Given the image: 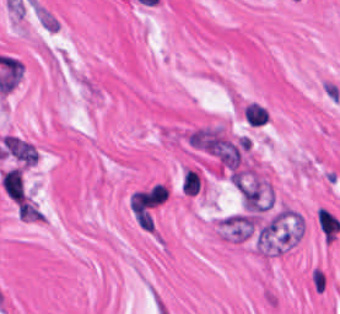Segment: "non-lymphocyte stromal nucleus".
I'll use <instances>...</instances> for the list:
<instances>
[{"label":"non-lymphocyte stromal nucleus","mask_w":340,"mask_h":314,"mask_svg":"<svg viewBox=\"0 0 340 314\" xmlns=\"http://www.w3.org/2000/svg\"><path fill=\"white\" fill-rule=\"evenodd\" d=\"M300 233L299 216L280 209L261 222L255 230V240L260 249H283L296 242Z\"/></svg>","instance_id":"non-lymphocyte-stromal-nucleus-1"},{"label":"non-lymphocyte stromal nucleus","mask_w":340,"mask_h":314,"mask_svg":"<svg viewBox=\"0 0 340 314\" xmlns=\"http://www.w3.org/2000/svg\"><path fill=\"white\" fill-rule=\"evenodd\" d=\"M235 186L244 210H264L268 194L260 180L242 172H235Z\"/></svg>","instance_id":"non-lymphocyte-stromal-nucleus-2"},{"label":"non-lymphocyte stromal nucleus","mask_w":340,"mask_h":314,"mask_svg":"<svg viewBox=\"0 0 340 314\" xmlns=\"http://www.w3.org/2000/svg\"><path fill=\"white\" fill-rule=\"evenodd\" d=\"M255 217L249 211L226 215L220 223L221 231L231 239H245L253 232Z\"/></svg>","instance_id":"non-lymphocyte-stromal-nucleus-3"},{"label":"non-lymphocyte stromal nucleus","mask_w":340,"mask_h":314,"mask_svg":"<svg viewBox=\"0 0 340 314\" xmlns=\"http://www.w3.org/2000/svg\"><path fill=\"white\" fill-rule=\"evenodd\" d=\"M5 151L16 158L21 163H34L37 159V150L26 140L12 135H5Z\"/></svg>","instance_id":"non-lymphocyte-stromal-nucleus-4"}]
</instances>
